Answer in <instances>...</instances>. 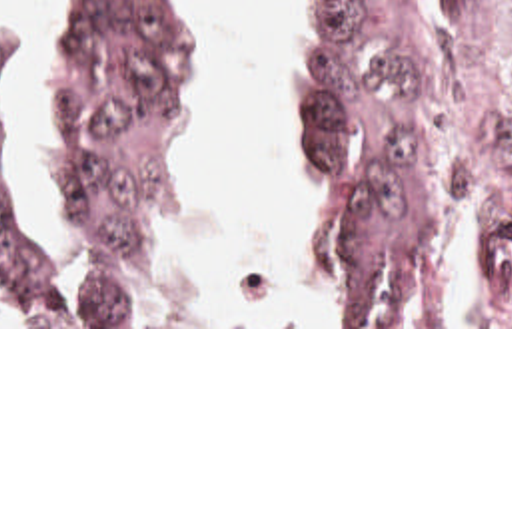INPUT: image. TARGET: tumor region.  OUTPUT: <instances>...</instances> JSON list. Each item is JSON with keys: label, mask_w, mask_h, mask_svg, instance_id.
Segmentation results:
<instances>
[{"label": "tumor region", "mask_w": 512, "mask_h": 512, "mask_svg": "<svg viewBox=\"0 0 512 512\" xmlns=\"http://www.w3.org/2000/svg\"><path fill=\"white\" fill-rule=\"evenodd\" d=\"M512 4V0H508ZM428 0H304L308 65L282 139L342 325H434L444 201L416 115ZM14 34H0V325H156L160 213L196 97L192 0H68L64 247L28 221L14 149ZM462 293L512 325V121L484 133L462 213Z\"/></svg>", "instance_id": "tumor-region-1"}]
</instances>
